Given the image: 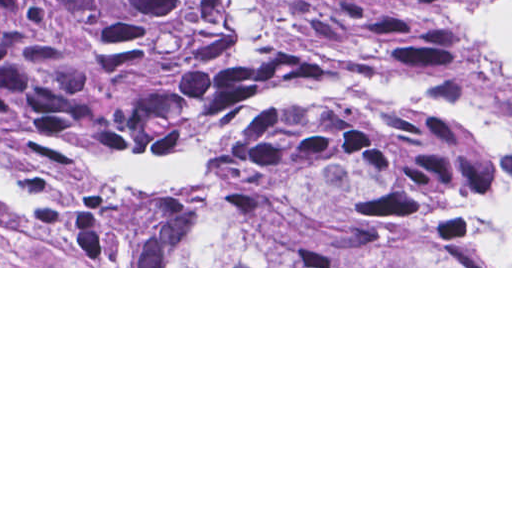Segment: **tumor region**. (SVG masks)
<instances>
[{"instance_id":"tumor-region-1","label":"tumor region","mask_w":512,"mask_h":512,"mask_svg":"<svg viewBox=\"0 0 512 512\" xmlns=\"http://www.w3.org/2000/svg\"><path fill=\"white\" fill-rule=\"evenodd\" d=\"M0 208L54 266H512V0H0Z\"/></svg>"}]
</instances>
